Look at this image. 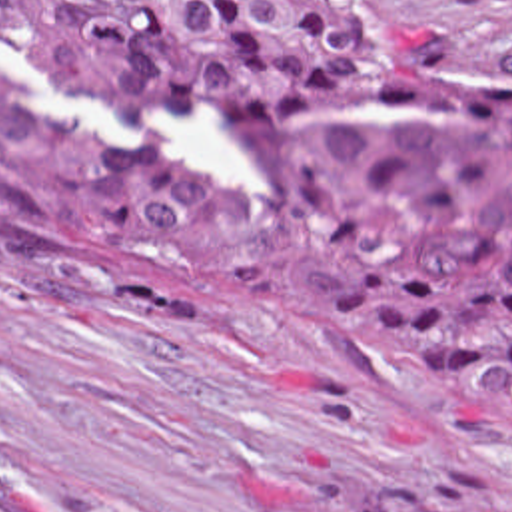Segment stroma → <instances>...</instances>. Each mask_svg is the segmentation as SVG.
<instances>
[{
    "label": "stroma",
    "instance_id": "stroma-1",
    "mask_svg": "<svg viewBox=\"0 0 512 512\" xmlns=\"http://www.w3.org/2000/svg\"><path fill=\"white\" fill-rule=\"evenodd\" d=\"M383 1L444 79H512V0ZM0 63L121 155L255 203V155L211 109ZM0 512H512V437L464 383L351 339L83 293L0 211Z\"/></svg>",
    "mask_w": 512,
    "mask_h": 512
}]
</instances>
